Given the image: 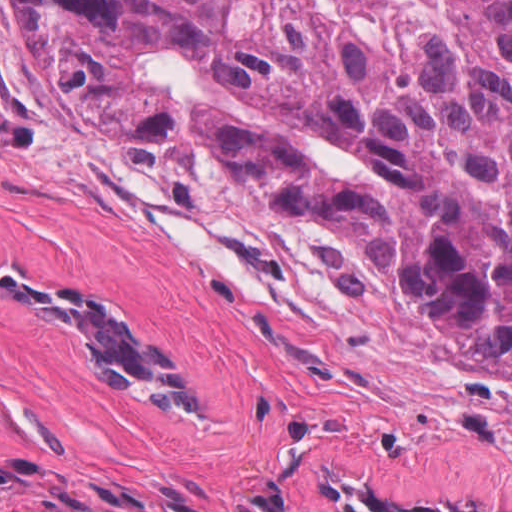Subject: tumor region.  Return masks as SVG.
<instances>
[{"label": "tumor region", "instance_id": "obj_1", "mask_svg": "<svg viewBox=\"0 0 512 512\" xmlns=\"http://www.w3.org/2000/svg\"><path fill=\"white\" fill-rule=\"evenodd\" d=\"M10 1L74 107L352 229L512 380V0Z\"/></svg>", "mask_w": 512, "mask_h": 512}]
</instances>
